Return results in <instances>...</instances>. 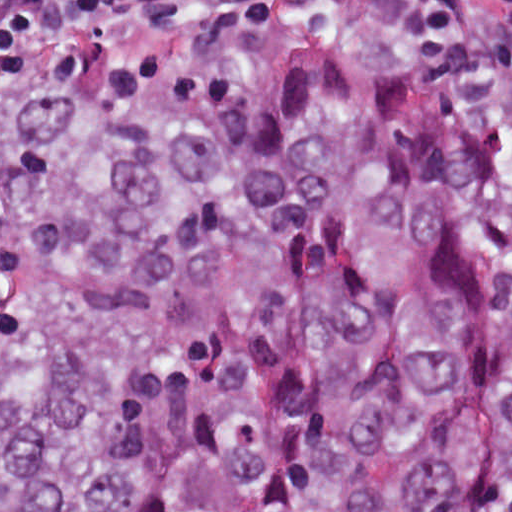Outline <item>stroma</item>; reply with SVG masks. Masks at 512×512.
I'll use <instances>...</instances> for the list:
<instances>
[{
    "mask_svg": "<svg viewBox=\"0 0 512 512\" xmlns=\"http://www.w3.org/2000/svg\"><path fill=\"white\" fill-rule=\"evenodd\" d=\"M32 48L0 52V90L16 67L22 55Z\"/></svg>",
    "mask_w": 512,
    "mask_h": 512,
    "instance_id": "obj_1",
    "label": "stroma"
}]
</instances>
